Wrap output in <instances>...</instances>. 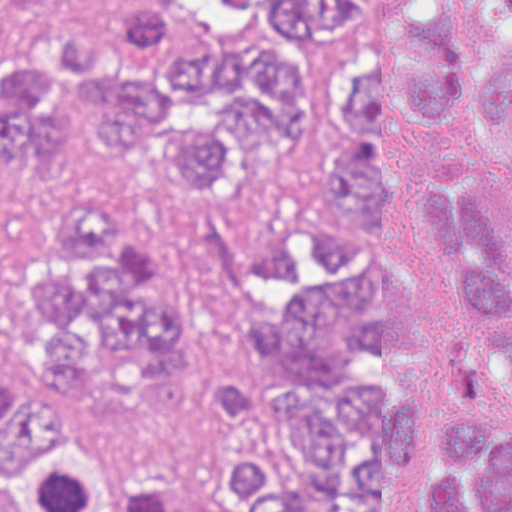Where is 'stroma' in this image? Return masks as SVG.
Here are the masks:
<instances>
[{
  "mask_svg": "<svg viewBox=\"0 0 512 512\" xmlns=\"http://www.w3.org/2000/svg\"><path fill=\"white\" fill-rule=\"evenodd\" d=\"M124 0H33L0 20V43L33 30L111 27ZM204 43L227 46L261 36L271 0H173ZM455 32L482 65L492 50L489 16L481 0H450ZM66 143L92 193H109L132 236L150 244L175 274L197 323V380L210 389H238V315L260 238L296 207L384 244L418 284L431 286L439 269L422 242L387 224L382 230L349 220L325 177L319 155L306 150L242 164L233 196H197L170 185L158 155L104 150L86 125L66 123ZM447 160L479 177L512 221V162L481 104L467 117L424 116L399 127L395 170ZM22 185L0 176V349L19 280V210Z\"/></svg>",
  "mask_w": 512,
  "mask_h": 512,
  "instance_id": "1",
  "label": "stroma"
}]
</instances>
